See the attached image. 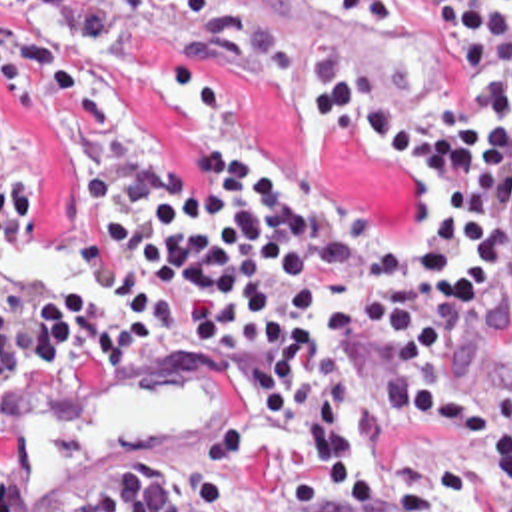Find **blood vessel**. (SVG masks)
I'll use <instances>...</instances> for the list:
<instances>
[{
    "mask_svg": "<svg viewBox=\"0 0 512 512\" xmlns=\"http://www.w3.org/2000/svg\"><path fill=\"white\" fill-rule=\"evenodd\" d=\"M196 24L242 26L246 0H162ZM150 342L112 360L30 354L0 416V512H70L142 456L210 448L252 390L246 354Z\"/></svg>",
    "mask_w": 512,
    "mask_h": 512,
    "instance_id": "obj_1",
    "label": "blood vessel"
}]
</instances>
